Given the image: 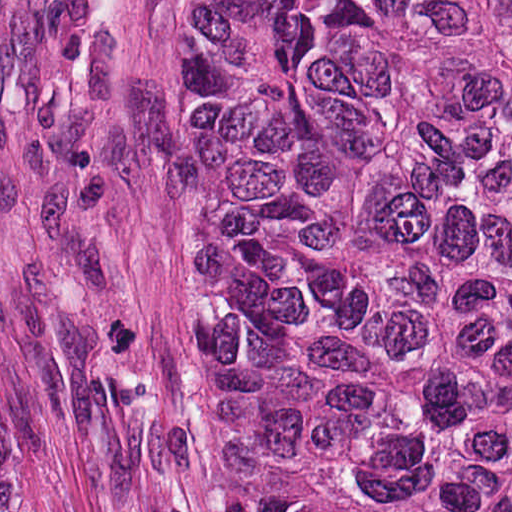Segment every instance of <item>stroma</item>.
Instances as JSON below:
<instances>
[{
  "mask_svg": "<svg viewBox=\"0 0 512 512\" xmlns=\"http://www.w3.org/2000/svg\"><path fill=\"white\" fill-rule=\"evenodd\" d=\"M184 0H0V402L25 512H193Z\"/></svg>",
  "mask_w": 512,
  "mask_h": 512,
  "instance_id": "obj_1",
  "label": "stroma"
}]
</instances>
